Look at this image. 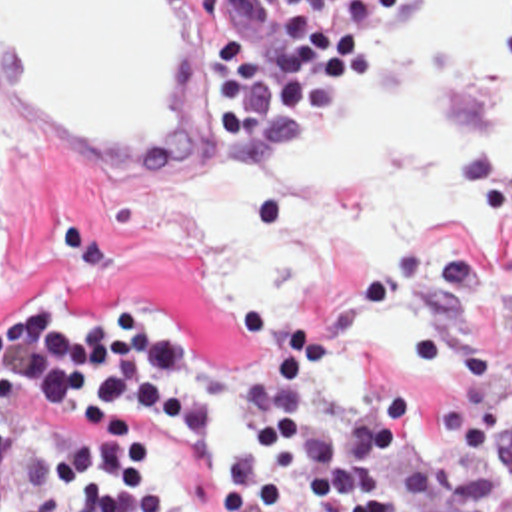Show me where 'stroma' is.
Here are the masks:
<instances>
[{
    "mask_svg": "<svg viewBox=\"0 0 512 512\" xmlns=\"http://www.w3.org/2000/svg\"><path fill=\"white\" fill-rule=\"evenodd\" d=\"M451 1H413L395 23L379 71L349 87L325 125L251 165H217L225 125L209 93L195 117L189 157L167 173L119 167L43 127H13L3 157V217L15 237V261L0 267V323L19 319L37 299L79 323L109 305H147L197 343L199 359L177 380L205 390L209 422L187 430L153 422V478L197 512H215V488L247 426L245 390L271 359L251 345L247 309L269 303L279 323L307 325L317 335L325 369L309 410L339 418L347 408L327 402V375L353 319L393 277L407 303L447 331V347L425 359L377 355L409 404V448L395 460L397 476L403 482L423 454L445 460L447 494L421 512H503L512 496V153L469 159L475 203L497 241L451 231L395 257L349 255L321 293L247 299L231 329L217 321L209 287L179 245L139 219L147 197L165 187L229 185L307 159L331 129L373 99L391 61ZM291 3L219 0V33L265 49ZM505 59L512 63V33Z\"/></svg>",
    "mask_w": 512,
    "mask_h": 512,
    "instance_id": "35a3bbf8",
    "label": "stroma"
}]
</instances>
